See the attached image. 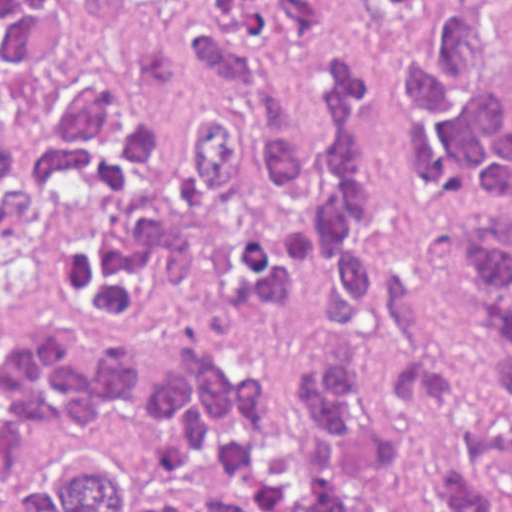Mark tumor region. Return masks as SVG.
Wrapping results in <instances>:
<instances>
[{
  "label": "tumor region",
  "mask_w": 512,
  "mask_h": 512,
  "mask_svg": "<svg viewBox=\"0 0 512 512\" xmlns=\"http://www.w3.org/2000/svg\"><path fill=\"white\" fill-rule=\"evenodd\" d=\"M368 16L424 0H350ZM446 4L396 54L407 163L474 210L444 247L456 367L364 352L266 364L211 326L1 341V462L59 512H512V88L499 0ZM336 0H1V294L283 306L308 252L321 330L401 350L413 290L369 247L393 176L342 39L306 148L282 53L326 47Z\"/></svg>",
  "instance_id": "obj_1"
}]
</instances>
